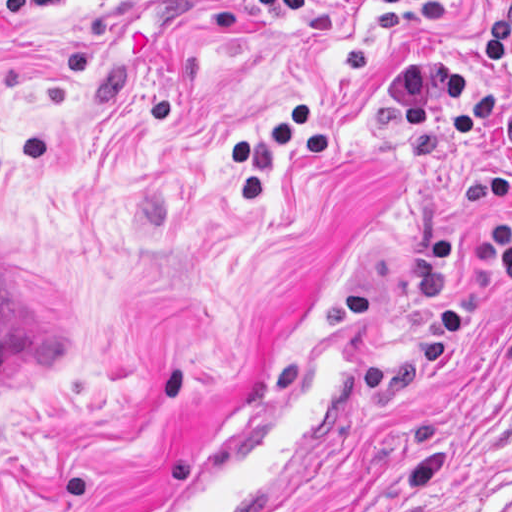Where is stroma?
I'll list each match as a JSON object with an SVG mask.
<instances>
[{
	"label": "stroma",
	"instance_id": "obj_1",
	"mask_svg": "<svg viewBox=\"0 0 512 512\" xmlns=\"http://www.w3.org/2000/svg\"><path fill=\"white\" fill-rule=\"evenodd\" d=\"M458 1L373 55L332 153L281 159L247 204L223 141L336 82L374 3L0 0V512H135L370 280L374 420L309 512H512V286L436 341L468 268L418 255L498 229L463 179L503 153L478 129L407 139L386 92L458 54L512 101V53H482L507 0ZM1 256L89 307V344L24 385H1Z\"/></svg>",
	"mask_w": 512,
	"mask_h": 512
}]
</instances>
